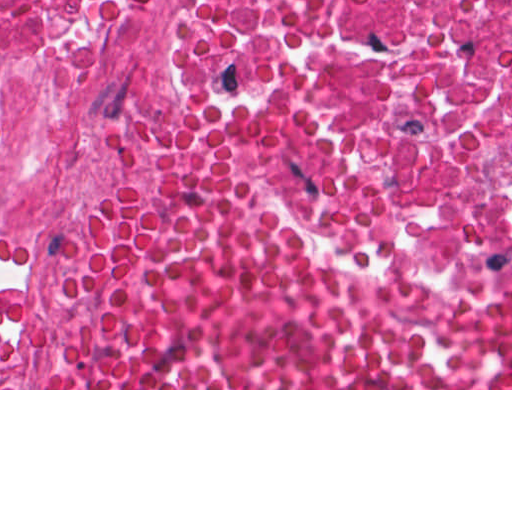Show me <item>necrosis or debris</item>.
I'll return each instance as SVG.
<instances>
[{
    "label": "necrosis or debris",
    "instance_id": "4bbe7bcc",
    "mask_svg": "<svg viewBox=\"0 0 512 512\" xmlns=\"http://www.w3.org/2000/svg\"><path fill=\"white\" fill-rule=\"evenodd\" d=\"M226 43L231 78L329 115L407 260L512 280V0H0V386L53 330L106 105L148 63Z\"/></svg>",
    "mask_w": 512,
    "mask_h": 512
}]
</instances>
